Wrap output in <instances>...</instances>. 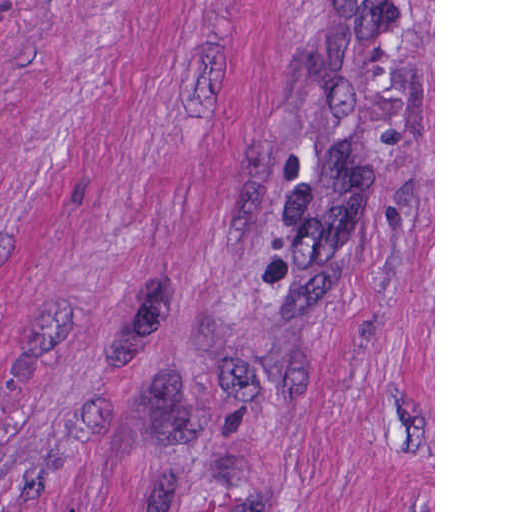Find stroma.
Returning a JSON list of instances; mask_svg holds the SVG:
<instances>
[{
    "label": "stroma",
    "mask_w": 512,
    "mask_h": 512,
    "mask_svg": "<svg viewBox=\"0 0 512 512\" xmlns=\"http://www.w3.org/2000/svg\"><path fill=\"white\" fill-rule=\"evenodd\" d=\"M326 1H433V192L274 289ZM0 512H435V0H0Z\"/></svg>",
    "instance_id": "obj_1"
}]
</instances>
